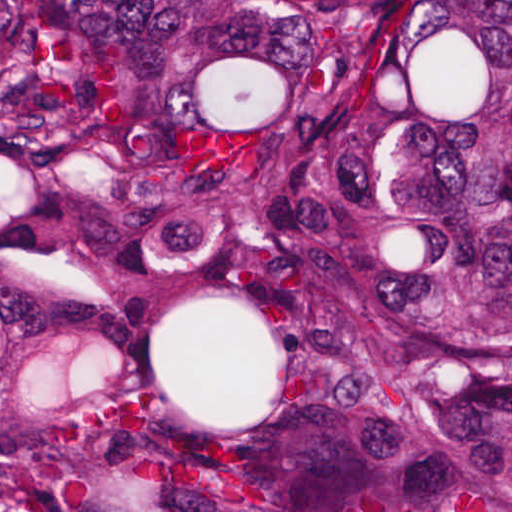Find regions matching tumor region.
Here are the masks:
<instances>
[{
    "label": "tumor region",
    "instance_id": "tumor-region-1",
    "mask_svg": "<svg viewBox=\"0 0 512 512\" xmlns=\"http://www.w3.org/2000/svg\"><path fill=\"white\" fill-rule=\"evenodd\" d=\"M4 134L42 512H512V1H5Z\"/></svg>",
    "mask_w": 512,
    "mask_h": 512
}]
</instances>
